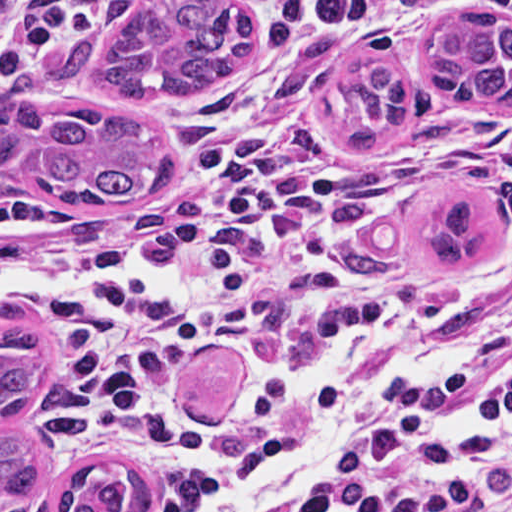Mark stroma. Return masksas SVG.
<instances>
[{
    "label": "stroma",
    "mask_w": 512,
    "mask_h": 512,
    "mask_svg": "<svg viewBox=\"0 0 512 512\" xmlns=\"http://www.w3.org/2000/svg\"><path fill=\"white\" fill-rule=\"evenodd\" d=\"M65 0H0V32ZM254 19L251 45L220 81L182 102H115L97 90L54 81L45 66L61 44L27 58L3 88L18 78L35 82L43 104L93 108L143 120L161 134L173 166V182L155 199L105 208L130 225L153 232L198 191L195 158L205 127L228 101L236 70L263 42L287 0H247ZM437 17V16H436ZM358 42L320 65L304 91L306 132L345 156H367L369 169L349 190L351 206L367 227L364 267L375 287L357 316L282 329L227 335L212 340L181 377L162 422L169 431H191L234 421L257 410L274 379L304 366L333 374L337 392L331 416L332 450L413 370L512 282V106H453L441 103L426 79L424 55L435 18ZM392 61L412 94L406 125L386 143H351L358 107L344 82L354 67ZM0 193L82 205L55 196L25 176L0 177ZM472 194L492 227V249L462 269L431 266L428 250L435 213L446 199ZM41 329V328H40ZM45 370L40 404L29 429L56 467L45 439L57 350L45 331ZM295 441L266 455L220 490L283 460ZM331 450V451H332ZM150 512L179 508L149 466ZM18 512H51L46 500ZM293 512V511H292Z\"/></svg>",
    "instance_id": "obj_1"
}]
</instances>
